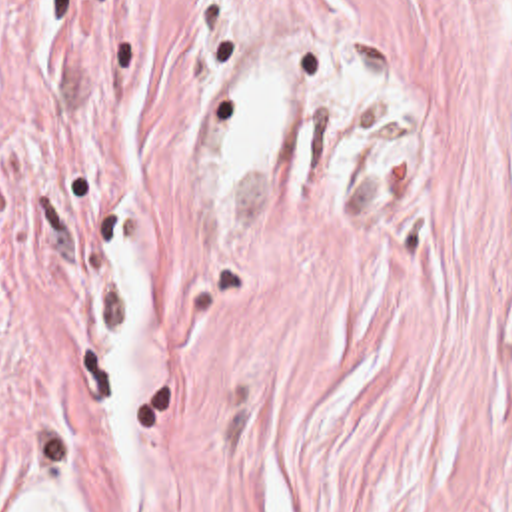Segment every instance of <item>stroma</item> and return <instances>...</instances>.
<instances>
[{"label": "stroma", "instance_id": "obj_1", "mask_svg": "<svg viewBox=\"0 0 512 512\" xmlns=\"http://www.w3.org/2000/svg\"><path fill=\"white\" fill-rule=\"evenodd\" d=\"M512 512V0H0V512Z\"/></svg>", "mask_w": 512, "mask_h": 512}]
</instances>
